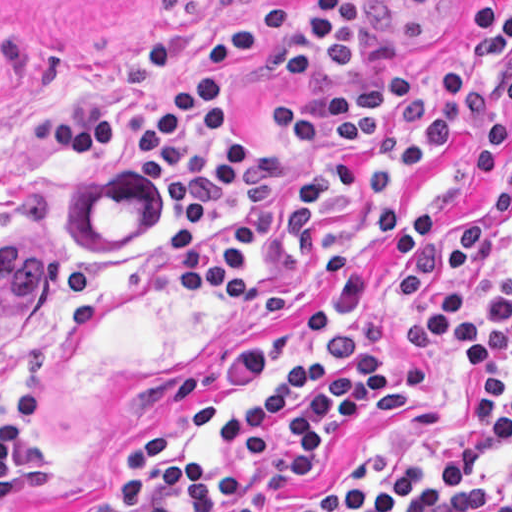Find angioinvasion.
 <instances>
[{"instance_id": "obj_1", "label": "angioinvasion", "mask_w": 512, "mask_h": 512, "mask_svg": "<svg viewBox=\"0 0 512 512\" xmlns=\"http://www.w3.org/2000/svg\"><path fill=\"white\" fill-rule=\"evenodd\" d=\"M54 280L52 239L32 227L0 232V355L41 311Z\"/></svg>"}]
</instances>
